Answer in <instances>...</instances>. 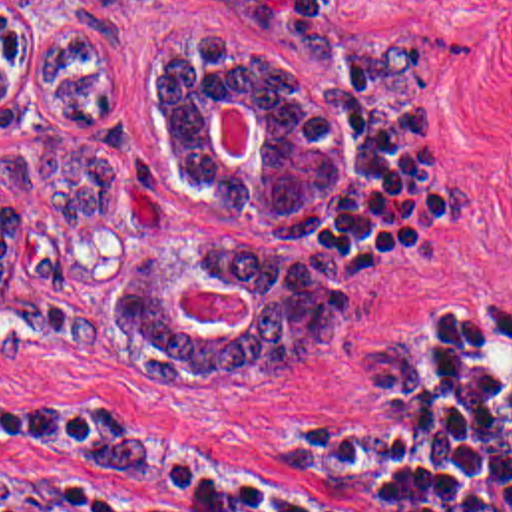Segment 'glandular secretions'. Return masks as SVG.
<instances>
[{"instance_id":"glandular-secretions-1","label":"glandular secretions","mask_w":512,"mask_h":512,"mask_svg":"<svg viewBox=\"0 0 512 512\" xmlns=\"http://www.w3.org/2000/svg\"><path fill=\"white\" fill-rule=\"evenodd\" d=\"M224 99H216V105H214V115H212V143H214V147H216V151L222 154L220 151V145H218V111H220V103H222ZM254 145V143H252ZM222 158H224V154H222ZM236 288L246 296V288L244 286H240V284H236ZM180 290H184V288H180ZM180 290L176 292V296H174V308L178 310V314L182 316V318H188L184 312H182V308H180V304H178V296H180Z\"/></svg>"}]
</instances>
